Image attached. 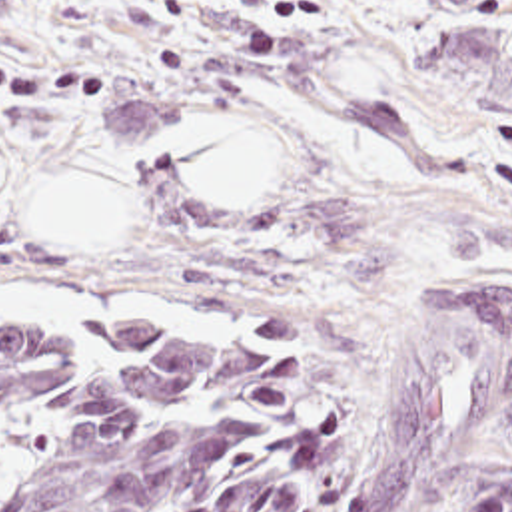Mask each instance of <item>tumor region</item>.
I'll return each instance as SVG.
<instances>
[{
    "instance_id": "tumor-region-1",
    "label": "tumor region",
    "mask_w": 512,
    "mask_h": 512,
    "mask_svg": "<svg viewBox=\"0 0 512 512\" xmlns=\"http://www.w3.org/2000/svg\"><path fill=\"white\" fill-rule=\"evenodd\" d=\"M512 412V281L442 253L410 313L351 512H416ZM333 379L261 325L0 323V512H325ZM466 512H512V472Z\"/></svg>"
}]
</instances>
